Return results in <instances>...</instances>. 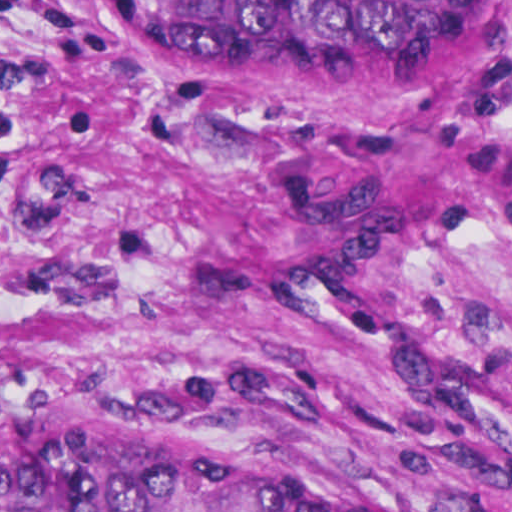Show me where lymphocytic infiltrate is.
I'll use <instances>...</instances> for the list:
<instances>
[{
    "mask_svg": "<svg viewBox=\"0 0 512 512\" xmlns=\"http://www.w3.org/2000/svg\"><path fill=\"white\" fill-rule=\"evenodd\" d=\"M43 0H0V17L18 15Z\"/></svg>",
    "mask_w": 512,
    "mask_h": 512,
    "instance_id": "1",
    "label": "lymphocytic infiltrate"
}]
</instances>
